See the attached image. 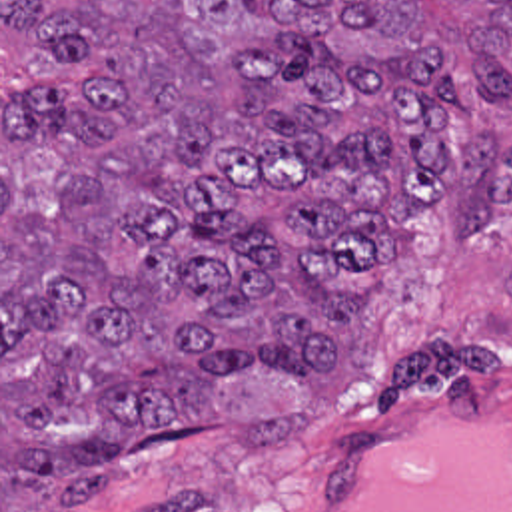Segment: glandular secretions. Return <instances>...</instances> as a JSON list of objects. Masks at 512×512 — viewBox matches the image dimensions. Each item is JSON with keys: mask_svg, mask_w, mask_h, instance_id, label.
<instances>
[{"mask_svg": "<svg viewBox=\"0 0 512 512\" xmlns=\"http://www.w3.org/2000/svg\"><path fill=\"white\" fill-rule=\"evenodd\" d=\"M319 512H512V418L457 412L379 432L341 460Z\"/></svg>", "mask_w": 512, "mask_h": 512, "instance_id": "glandular-secretions-1", "label": "glandular secretions"}]
</instances>
